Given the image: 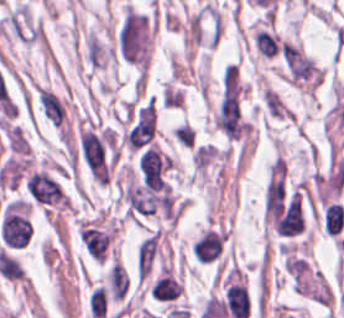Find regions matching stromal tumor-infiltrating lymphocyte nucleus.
I'll return each instance as SVG.
<instances>
[{"label":"stromal tumor-infiltrating lymphocyte nucleus","instance_id":"obj_1","mask_svg":"<svg viewBox=\"0 0 344 318\" xmlns=\"http://www.w3.org/2000/svg\"><path fill=\"white\" fill-rule=\"evenodd\" d=\"M324 227L329 237L340 235L344 227V206L332 203L324 214Z\"/></svg>","mask_w":344,"mask_h":318},{"label":"stromal tumor-infiltrating lymphocyte nucleus","instance_id":"obj_2","mask_svg":"<svg viewBox=\"0 0 344 318\" xmlns=\"http://www.w3.org/2000/svg\"><path fill=\"white\" fill-rule=\"evenodd\" d=\"M173 134L179 144L191 148L195 137L194 128L183 122L174 128Z\"/></svg>","mask_w":344,"mask_h":318}]
</instances>
